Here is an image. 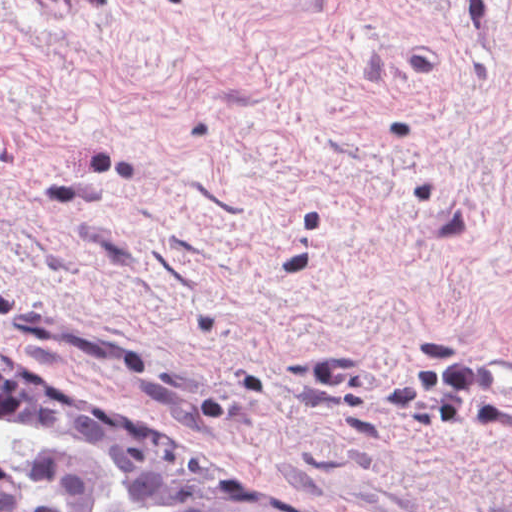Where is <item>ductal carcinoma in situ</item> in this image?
Here are the masks:
<instances>
[{
    "label": "ductal carcinoma in situ",
    "instance_id": "1",
    "mask_svg": "<svg viewBox=\"0 0 512 512\" xmlns=\"http://www.w3.org/2000/svg\"><path fill=\"white\" fill-rule=\"evenodd\" d=\"M0 415L47 428L97 456L145 504L167 505L172 512H267L124 450L98 431L57 385L1 348ZM29 473L44 495V503L37 509L27 508L11 478L0 468V512L97 511L104 479L76 457L36 453Z\"/></svg>",
    "mask_w": 512,
    "mask_h": 512
}]
</instances>
